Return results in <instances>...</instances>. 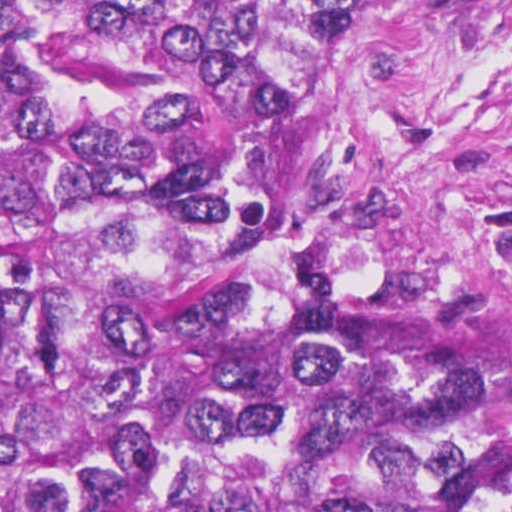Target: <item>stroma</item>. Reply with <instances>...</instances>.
Here are the masks:
<instances>
[{"mask_svg": "<svg viewBox=\"0 0 512 512\" xmlns=\"http://www.w3.org/2000/svg\"><path fill=\"white\" fill-rule=\"evenodd\" d=\"M323 169L334 231L391 311L512 386V0H353Z\"/></svg>", "mask_w": 512, "mask_h": 512, "instance_id": "obj_1", "label": "stroma"}]
</instances>
